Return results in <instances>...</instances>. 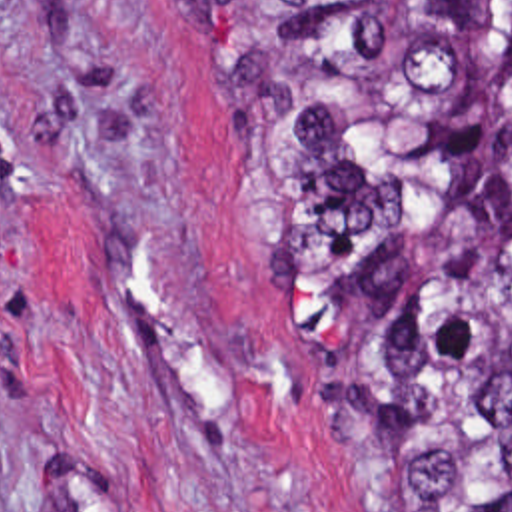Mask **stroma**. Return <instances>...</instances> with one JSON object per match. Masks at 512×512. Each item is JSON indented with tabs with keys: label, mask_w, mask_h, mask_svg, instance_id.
Listing matches in <instances>:
<instances>
[{
	"label": "stroma",
	"mask_w": 512,
	"mask_h": 512,
	"mask_svg": "<svg viewBox=\"0 0 512 512\" xmlns=\"http://www.w3.org/2000/svg\"><path fill=\"white\" fill-rule=\"evenodd\" d=\"M238 150L184 0H0V512H382Z\"/></svg>",
	"instance_id": "obj_1"
}]
</instances>
